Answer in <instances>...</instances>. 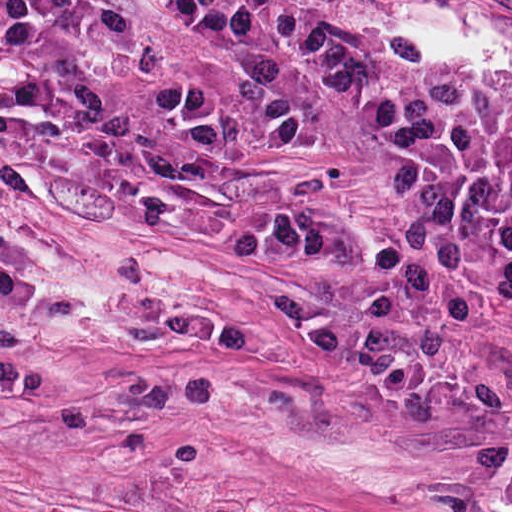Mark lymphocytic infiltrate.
I'll list each match as a JSON object with an SVG mask.
<instances>
[{"mask_svg": "<svg viewBox=\"0 0 512 512\" xmlns=\"http://www.w3.org/2000/svg\"><path fill=\"white\" fill-rule=\"evenodd\" d=\"M178 5L182 20L215 49H258L281 40L370 81L399 140L405 176L394 189L408 204V219L369 253H351L340 218L332 216L233 227V260L261 265L310 254L339 270L374 271L385 281L381 295L339 310L391 302L460 330L473 328L474 294L512 329V125L373 82L368 62L295 33L267 35L238 0ZM0 66L54 94L97 100L104 80L156 73L157 57L106 0H0ZM162 96L190 125L173 89ZM274 309L304 308L292 299Z\"/></svg>", "mask_w": 512, "mask_h": 512, "instance_id": "obj_1", "label": "lymphocytic infiltrate"}]
</instances>
